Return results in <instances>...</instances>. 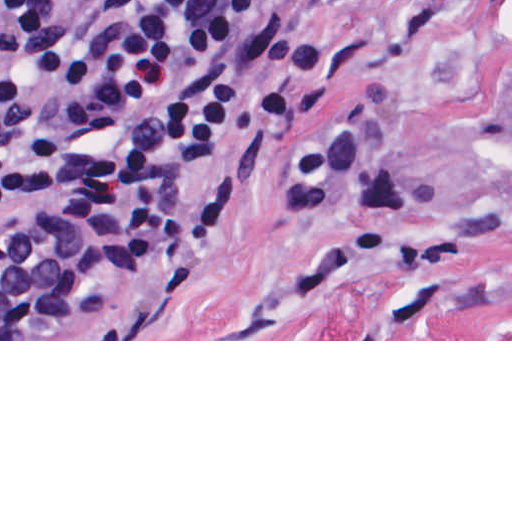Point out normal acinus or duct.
<instances>
[{
  "mask_svg": "<svg viewBox=\"0 0 512 512\" xmlns=\"http://www.w3.org/2000/svg\"><path fill=\"white\" fill-rule=\"evenodd\" d=\"M168 261L124 237L41 261L0 237V339H123L157 303Z\"/></svg>",
  "mask_w": 512,
  "mask_h": 512,
  "instance_id": "1",
  "label": "normal acinus or duct"
}]
</instances>
